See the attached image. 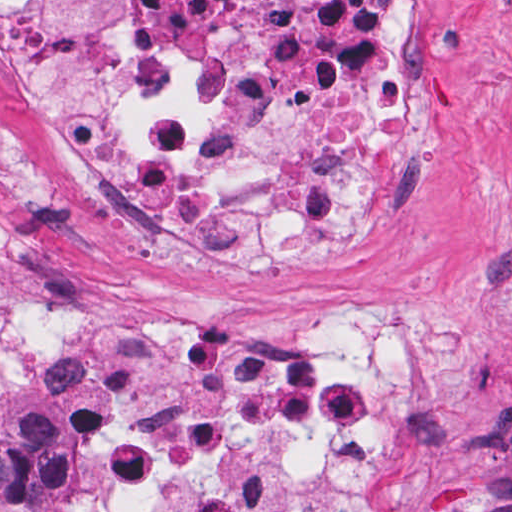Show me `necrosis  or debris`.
<instances>
[{
    "mask_svg": "<svg viewBox=\"0 0 512 512\" xmlns=\"http://www.w3.org/2000/svg\"><path fill=\"white\" fill-rule=\"evenodd\" d=\"M0 62L91 212L221 267L355 271L413 229L421 56L363 0H0ZM82 389L107 512H382L407 343L34 317L0 407Z\"/></svg>",
    "mask_w": 512,
    "mask_h": 512,
    "instance_id": "obj_1",
    "label": "necrosis or debris"
}]
</instances>
